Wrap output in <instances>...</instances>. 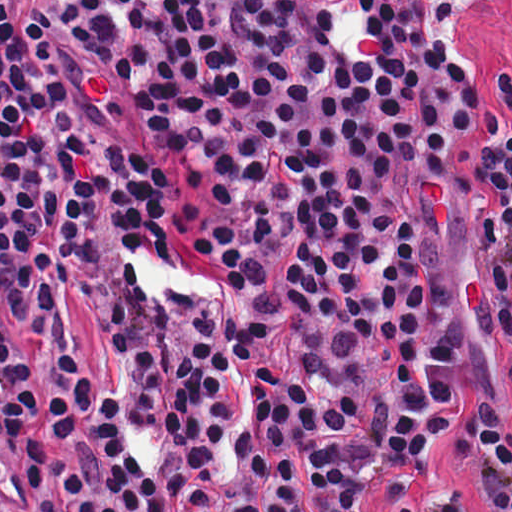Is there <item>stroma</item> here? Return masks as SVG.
I'll use <instances>...</instances> for the list:
<instances>
[{"label": "stroma", "mask_w": 512, "mask_h": 512, "mask_svg": "<svg viewBox=\"0 0 512 512\" xmlns=\"http://www.w3.org/2000/svg\"><path fill=\"white\" fill-rule=\"evenodd\" d=\"M455 27L460 45L492 98L489 79L500 70L512 73V0H464ZM476 213L470 195L451 200L438 227L423 245L424 267L449 302L457 323L459 362L456 408L431 449L444 473L474 512H500L461 447L483 407L502 410L512 426V371L494 337L479 318L473 293L469 227ZM119 254L109 232L99 247L98 286L89 294H63L68 334L98 390L119 403L124 435L144 469L156 466L161 443L157 421L132 410L122 360L111 331V312L119 286ZM305 512H329L298 471ZM393 483L384 479L344 512H393Z\"/></svg>", "instance_id": "1"}]
</instances>
